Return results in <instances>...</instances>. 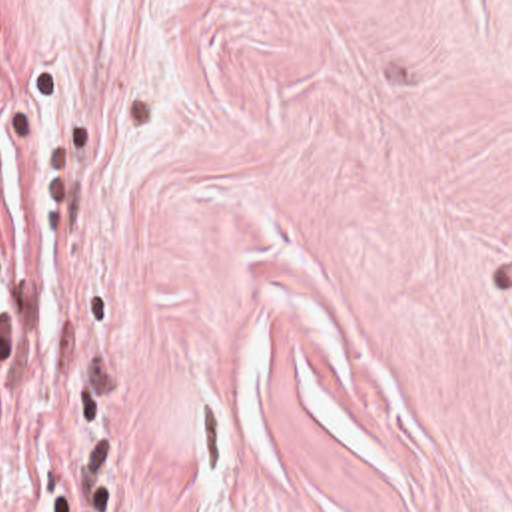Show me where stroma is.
Instances as JSON below:
<instances>
[{"mask_svg": "<svg viewBox=\"0 0 512 512\" xmlns=\"http://www.w3.org/2000/svg\"><path fill=\"white\" fill-rule=\"evenodd\" d=\"M0 512H512V0H0Z\"/></svg>", "mask_w": 512, "mask_h": 512, "instance_id": "obj_1", "label": "stroma"}]
</instances>
